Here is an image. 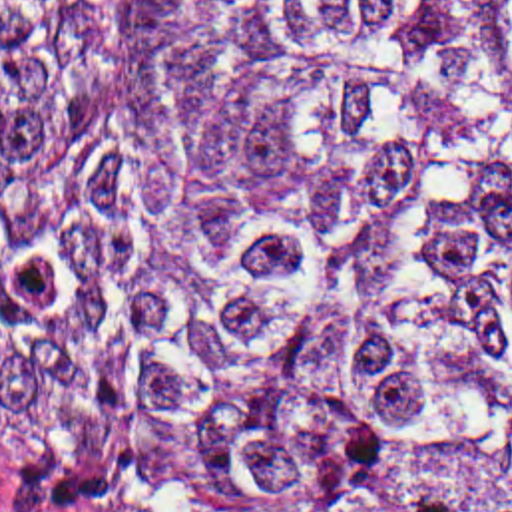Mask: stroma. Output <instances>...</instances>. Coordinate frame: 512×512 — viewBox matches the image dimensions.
Returning a JSON list of instances; mask_svg holds the SVG:
<instances>
[{
  "instance_id": "1",
  "label": "stroma",
  "mask_w": 512,
  "mask_h": 512,
  "mask_svg": "<svg viewBox=\"0 0 512 512\" xmlns=\"http://www.w3.org/2000/svg\"><path fill=\"white\" fill-rule=\"evenodd\" d=\"M0 512H126L54 481L0 439Z\"/></svg>"
}]
</instances>
